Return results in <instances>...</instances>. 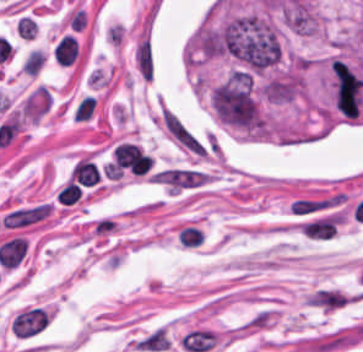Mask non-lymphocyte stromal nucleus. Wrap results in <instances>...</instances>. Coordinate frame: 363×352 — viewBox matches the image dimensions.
<instances>
[{
  "instance_id": "1",
  "label": "non-lymphocyte stromal nucleus",
  "mask_w": 363,
  "mask_h": 352,
  "mask_svg": "<svg viewBox=\"0 0 363 352\" xmlns=\"http://www.w3.org/2000/svg\"><path fill=\"white\" fill-rule=\"evenodd\" d=\"M51 206L45 203H38L15 210H11L1 218L0 225L6 227L23 226L39 220L49 213Z\"/></svg>"
},
{
  "instance_id": "2",
  "label": "non-lymphocyte stromal nucleus",
  "mask_w": 363,
  "mask_h": 352,
  "mask_svg": "<svg viewBox=\"0 0 363 352\" xmlns=\"http://www.w3.org/2000/svg\"><path fill=\"white\" fill-rule=\"evenodd\" d=\"M216 341V336L206 328H193L183 334L182 347L188 352H205L210 350Z\"/></svg>"
}]
</instances>
